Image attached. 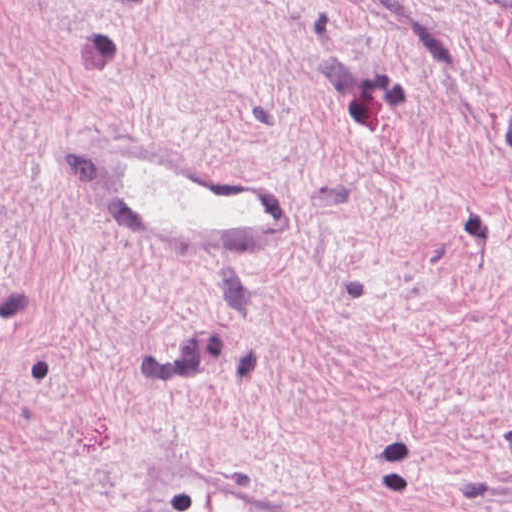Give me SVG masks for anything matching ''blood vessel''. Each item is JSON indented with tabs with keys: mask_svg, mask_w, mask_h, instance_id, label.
Segmentation results:
<instances>
[{
	"mask_svg": "<svg viewBox=\"0 0 512 512\" xmlns=\"http://www.w3.org/2000/svg\"><path fill=\"white\" fill-rule=\"evenodd\" d=\"M97 183L119 242L142 262L239 267L290 251L286 193L192 156L164 133L101 139Z\"/></svg>",
	"mask_w": 512,
	"mask_h": 512,
	"instance_id": "1",
	"label": "blood vessel"
}]
</instances>
